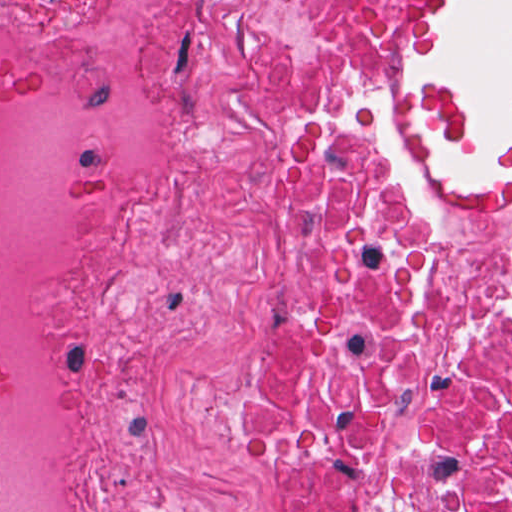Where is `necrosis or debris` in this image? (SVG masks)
I'll list each match as a JSON object with an SVG mask.
<instances>
[{
    "mask_svg": "<svg viewBox=\"0 0 512 512\" xmlns=\"http://www.w3.org/2000/svg\"><path fill=\"white\" fill-rule=\"evenodd\" d=\"M416 0H0V512H512V159L412 171Z\"/></svg>",
    "mask_w": 512,
    "mask_h": 512,
    "instance_id": "1",
    "label": "necrosis or debris"
}]
</instances>
